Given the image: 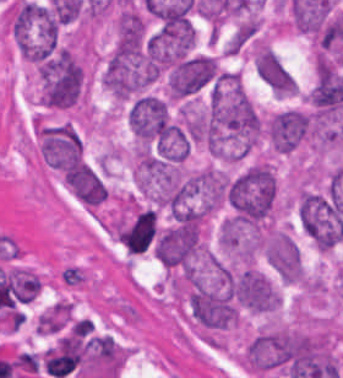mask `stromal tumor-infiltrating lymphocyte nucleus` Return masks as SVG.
Listing matches in <instances>:
<instances>
[{
    "instance_id": "stromal-tumor-infiltrating-lymphocyte-nucleus-1",
    "label": "stromal tumor-infiltrating lymphocyte nucleus",
    "mask_w": 343,
    "mask_h": 378,
    "mask_svg": "<svg viewBox=\"0 0 343 378\" xmlns=\"http://www.w3.org/2000/svg\"><path fill=\"white\" fill-rule=\"evenodd\" d=\"M85 356V344L79 336H65L43 354V364L51 376L64 378L78 367Z\"/></svg>"
}]
</instances>
